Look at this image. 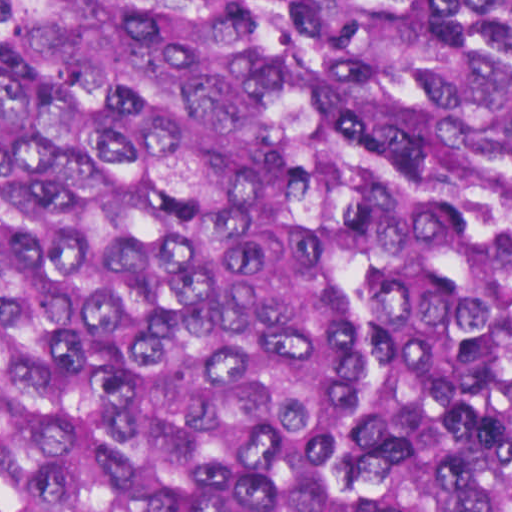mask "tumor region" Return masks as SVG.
Returning <instances> with one entry per match:
<instances>
[{
  "label": "tumor region",
  "mask_w": 512,
  "mask_h": 512,
  "mask_svg": "<svg viewBox=\"0 0 512 512\" xmlns=\"http://www.w3.org/2000/svg\"><path fill=\"white\" fill-rule=\"evenodd\" d=\"M0 512H512V0H0Z\"/></svg>",
  "instance_id": "tumor-region-1"
}]
</instances>
